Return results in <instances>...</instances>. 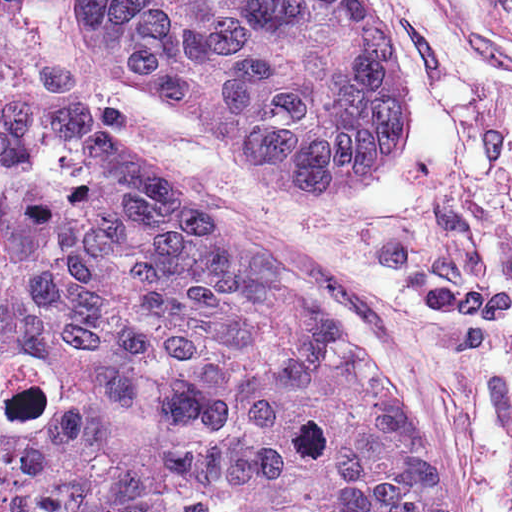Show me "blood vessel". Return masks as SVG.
<instances>
[{
  "mask_svg": "<svg viewBox=\"0 0 512 512\" xmlns=\"http://www.w3.org/2000/svg\"><path fill=\"white\" fill-rule=\"evenodd\" d=\"M455 42L512 65V0H418Z\"/></svg>",
  "mask_w": 512,
  "mask_h": 512,
  "instance_id": "8fb6f2fc",
  "label": "blood vessel"
}]
</instances>
